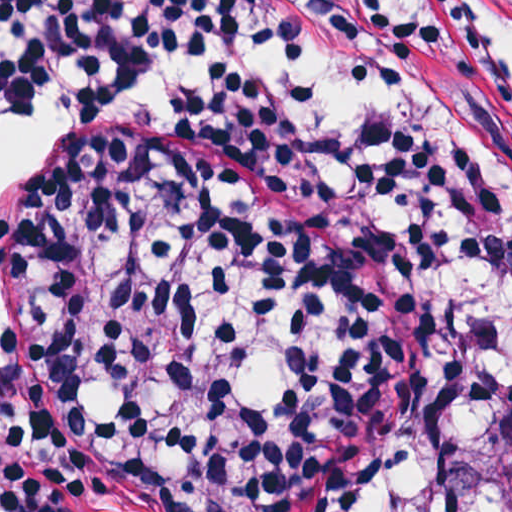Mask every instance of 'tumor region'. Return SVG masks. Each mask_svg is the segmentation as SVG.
Wrapping results in <instances>:
<instances>
[{
    "label": "tumor region",
    "instance_id": "1",
    "mask_svg": "<svg viewBox=\"0 0 512 512\" xmlns=\"http://www.w3.org/2000/svg\"><path fill=\"white\" fill-rule=\"evenodd\" d=\"M496 512H512V407L502 428V495Z\"/></svg>",
    "mask_w": 512,
    "mask_h": 512
}]
</instances>
